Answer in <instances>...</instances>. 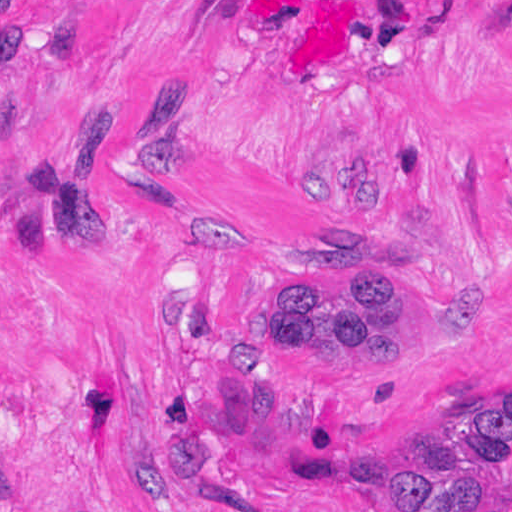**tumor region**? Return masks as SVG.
Returning a JSON list of instances; mask_svg holds the SVG:
<instances>
[{
	"label": "tumor region",
	"mask_w": 512,
	"mask_h": 512,
	"mask_svg": "<svg viewBox=\"0 0 512 512\" xmlns=\"http://www.w3.org/2000/svg\"><path fill=\"white\" fill-rule=\"evenodd\" d=\"M258 342L305 362L401 371L404 300L390 284L358 279L350 297L297 281L256 317ZM375 512H512V400L487 403L428 435Z\"/></svg>",
	"instance_id": "tumor-region-1"
}]
</instances>
